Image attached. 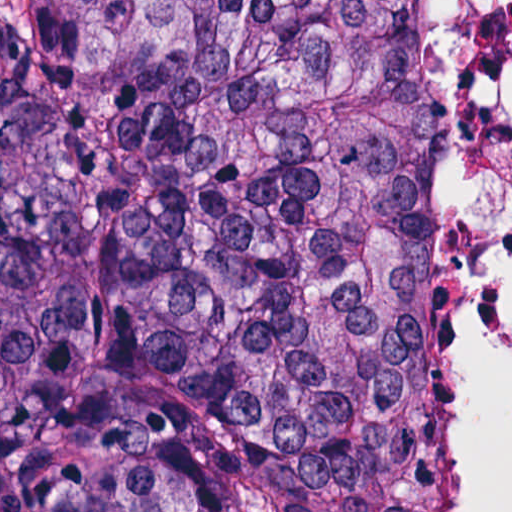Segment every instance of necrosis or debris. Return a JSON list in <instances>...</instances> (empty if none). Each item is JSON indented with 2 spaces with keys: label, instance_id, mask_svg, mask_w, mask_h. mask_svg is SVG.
<instances>
[{
  "label": "necrosis or debris",
  "instance_id": "4bbe7bcc",
  "mask_svg": "<svg viewBox=\"0 0 512 512\" xmlns=\"http://www.w3.org/2000/svg\"><path fill=\"white\" fill-rule=\"evenodd\" d=\"M511 292L512 0H435V512H467L477 487Z\"/></svg>",
  "mask_w": 512,
  "mask_h": 512
}]
</instances>
